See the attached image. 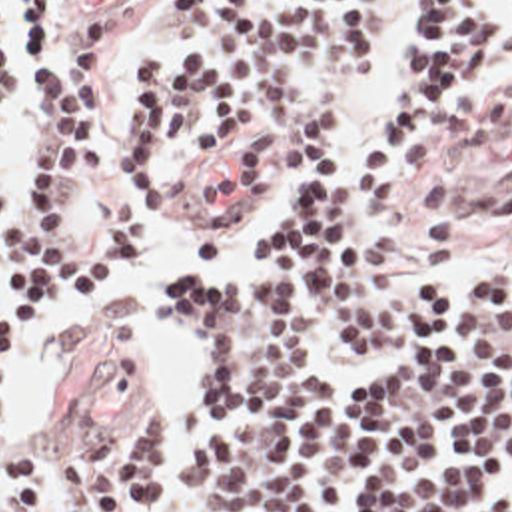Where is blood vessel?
Returning <instances> with one entry per match:
<instances>
[{"mask_svg":"<svg viewBox=\"0 0 512 512\" xmlns=\"http://www.w3.org/2000/svg\"><path fill=\"white\" fill-rule=\"evenodd\" d=\"M127 0H59L63 23L69 25H107Z\"/></svg>","mask_w":512,"mask_h":512,"instance_id":"blood-vessel-1","label":"blood vessel"}]
</instances>
